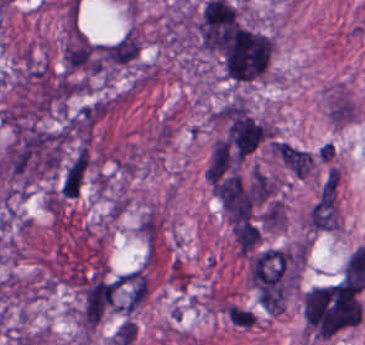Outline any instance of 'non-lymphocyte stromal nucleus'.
Here are the masks:
<instances>
[{
	"mask_svg": "<svg viewBox=\"0 0 365 345\" xmlns=\"http://www.w3.org/2000/svg\"><path fill=\"white\" fill-rule=\"evenodd\" d=\"M136 337L137 324L127 318L114 331L111 336V342L114 345H130L133 344Z\"/></svg>",
	"mask_w": 365,
	"mask_h": 345,
	"instance_id": "3746e769",
	"label": "non-lymphocyte stromal nucleus"
},
{
	"mask_svg": "<svg viewBox=\"0 0 365 345\" xmlns=\"http://www.w3.org/2000/svg\"><path fill=\"white\" fill-rule=\"evenodd\" d=\"M306 225L312 232L333 231L339 227V172L328 169L310 209Z\"/></svg>",
	"mask_w": 365,
	"mask_h": 345,
	"instance_id": "dd21d789",
	"label": "non-lymphocyte stromal nucleus"
},
{
	"mask_svg": "<svg viewBox=\"0 0 365 345\" xmlns=\"http://www.w3.org/2000/svg\"><path fill=\"white\" fill-rule=\"evenodd\" d=\"M271 149L292 172L299 176H307L314 162L310 153L280 142H273Z\"/></svg>",
	"mask_w": 365,
	"mask_h": 345,
	"instance_id": "a72fc3eb",
	"label": "non-lymphocyte stromal nucleus"
}]
</instances>
